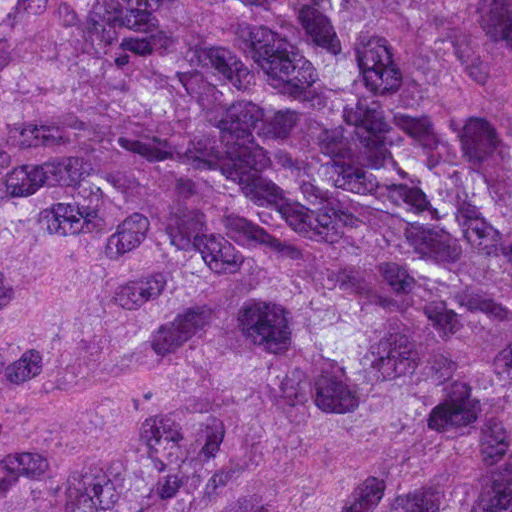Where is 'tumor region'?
Instances as JSON below:
<instances>
[{
	"instance_id": "tumor-region-1",
	"label": "tumor region",
	"mask_w": 512,
	"mask_h": 512,
	"mask_svg": "<svg viewBox=\"0 0 512 512\" xmlns=\"http://www.w3.org/2000/svg\"><path fill=\"white\" fill-rule=\"evenodd\" d=\"M0 512H512V0H0Z\"/></svg>"
}]
</instances>
